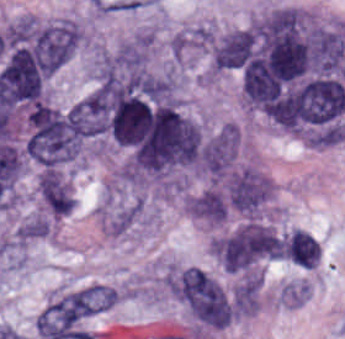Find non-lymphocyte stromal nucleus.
Masks as SVG:
<instances>
[{"label": "non-lymphocyte stromal nucleus", "instance_id": "obj_2", "mask_svg": "<svg viewBox=\"0 0 345 339\" xmlns=\"http://www.w3.org/2000/svg\"><path fill=\"white\" fill-rule=\"evenodd\" d=\"M170 291L196 317H223L222 289L196 266L191 265L173 273Z\"/></svg>", "mask_w": 345, "mask_h": 339}, {"label": "non-lymphocyte stromal nucleus", "instance_id": "obj_1", "mask_svg": "<svg viewBox=\"0 0 345 339\" xmlns=\"http://www.w3.org/2000/svg\"><path fill=\"white\" fill-rule=\"evenodd\" d=\"M219 186L226 207L244 217H254L270 198V180L254 166L235 165Z\"/></svg>", "mask_w": 345, "mask_h": 339}]
</instances>
